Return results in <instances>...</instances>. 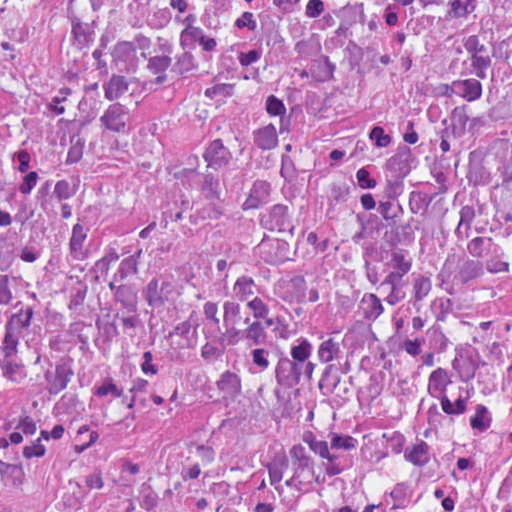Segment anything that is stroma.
<instances>
[{
    "mask_svg": "<svg viewBox=\"0 0 512 512\" xmlns=\"http://www.w3.org/2000/svg\"><path fill=\"white\" fill-rule=\"evenodd\" d=\"M1 1H512V0H0V512H1Z\"/></svg>",
    "mask_w": 512,
    "mask_h": 512,
    "instance_id": "stroma-1",
    "label": "stroma"
}]
</instances>
